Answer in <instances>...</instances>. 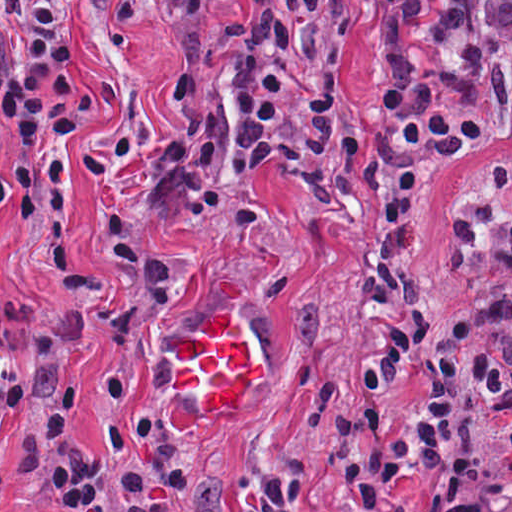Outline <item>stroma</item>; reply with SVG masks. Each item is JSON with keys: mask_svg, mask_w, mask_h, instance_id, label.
Returning a JSON list of instances; mask_svg holds the SVG:
<instances>
[{"mask_svg": "<svg viewBox=\"0 0 512 512\" xmlns=\"http://www.w3.org/2000/svg\"><path fill=\"white\" fill-rule=\"evenodd\" d=\"M66 17L86 99L188 54L154 0H48ZM307 0H265L252 26ZM248 26V27H249Z\"/></svg>", "mask_w": 512, "mask_h": 512, "instance_id": "35a3bbf8", "label": "stroma"}]
</instances>
